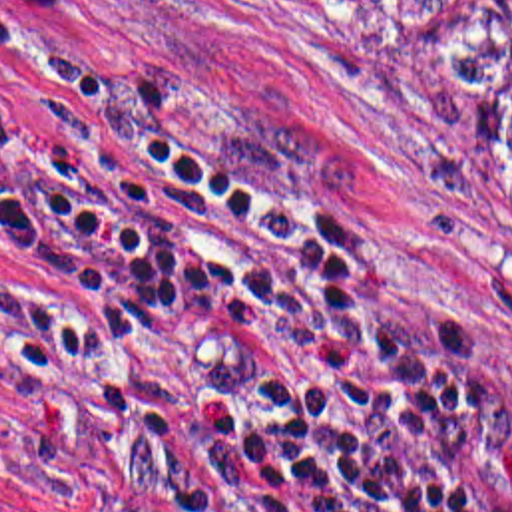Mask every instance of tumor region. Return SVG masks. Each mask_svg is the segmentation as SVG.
I'll return each instance as SVG.
<instances>
[{"mask_svg":"<svg viewBox=\"0 0 512 512\" xmlns=\"http://www.w3.org/2000/svg\"><path fill=\"white\" fill-rule=\"evenodd\" d=\"M490 132L512 158V87L490 103Z\"/></svg>","mask_w":512,"mask_h":512,"instance_id":"obj_1","label":"tumor region"}]
</instances>
